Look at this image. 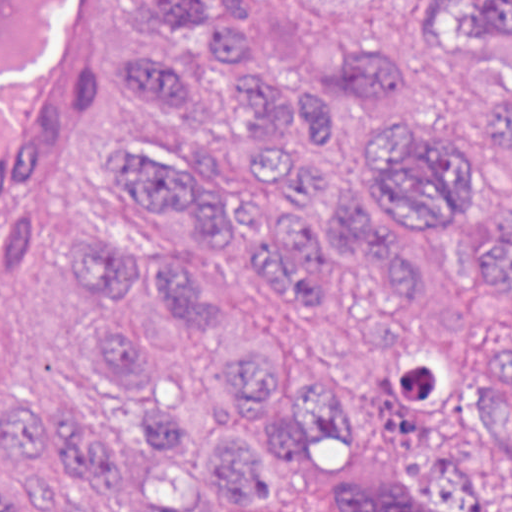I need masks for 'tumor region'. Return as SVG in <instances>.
<instances>
[{"label": "tumor region", "mask_w": 512, "mask_h": 512, "mask_svg": "<svg viewBox=\"0 0 512 512\" xmlns=\"http://www.w3.org/2000/svg\"><path fill=\"white\" fill-rule=\"evenodd\" d=\"M154 41L119 61L139 137L99 175L142 222L83 229L64 264L107 323L83 345L88 373L129 391L151 357L144 293L188 334L226 341L238 296L195 253L155 249L179 214L202 250L233 238L283 308L325 313L355 281L403 307L391 355L374 365L388 435L378 469H356L334 512H512V320L501 338L434 333L408 309L426 289L377 220L457 226L469 266L512 289V221L485 196L512 175V89L484 88L471 129L386 124L365 183L324 185L321 147L343 113L406 105L410 65L350 53L308 88L274 66L257 0H147ZM430 39L509 70L512 0H421ZM377 218V219H376ZM282 344L224 356L206 392H165L143 427L95 421L17 388L0 402V512H298L277 466L335 441L337 377Z\"/></svg>", "instance_id": "1"}]
</instances>
